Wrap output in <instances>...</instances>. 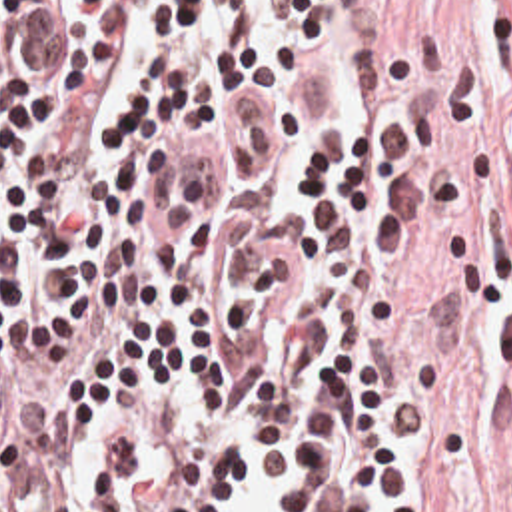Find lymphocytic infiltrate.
Masks as SVG:
<instances>
[{"instance_id":"1","label":"lymphocytic infiltrate","mask_w":512,"mask_h":512,"mask_svg":"<svg viewBox=\"0 0 512 512\" xmlns=\"http://www.w3.org/2000/svg\"><path fill=\"white\" fill-rule=\"evenodd\" d=\"M425 201L346 0H0V512H459Z\"/></svg>"}]
</instances>
